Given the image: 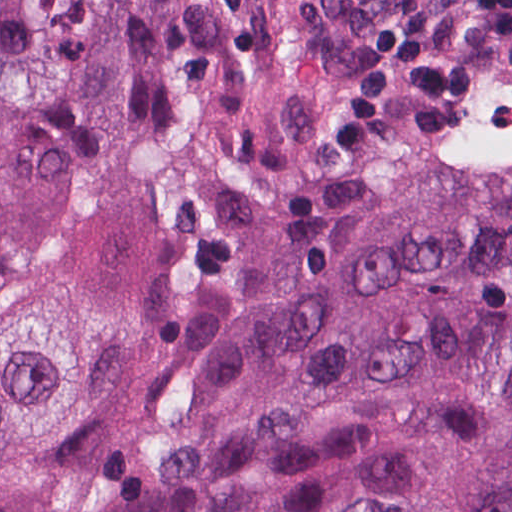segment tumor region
I'll use <instances>...</instances> for the list:
<instances>
[{
  "instance_id": "tumor-region-1",
  "label": "tumor region",
  "mask_w": 512,
  "mask_h": 512,
  "mask_svg": "<svg viewBox=\"0 0 512 512\" xmlns=\"http://www.w3.org/2000/svg\"><path fill=\"white\" fill-rule=\"evenodd\" d=\"M342 1L0 0V512H512V131L330 220Z\"/></svg>"
}]
</instances>
